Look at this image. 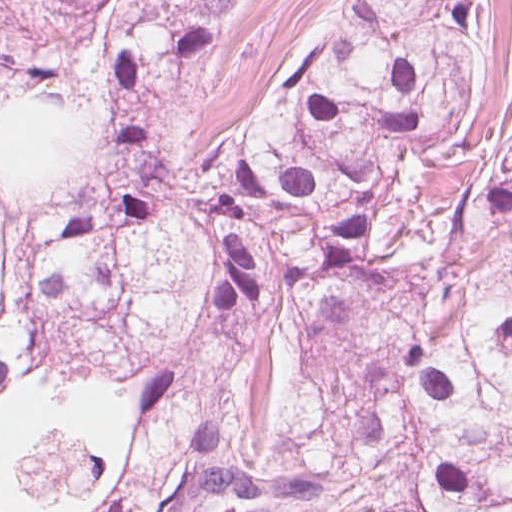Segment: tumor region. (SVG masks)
Returning <instances> with one entry per match:
<instances>
[{"mask_svg":"<svg viewBox=\"0 0 512 512\" xmlns=\"http://www.w3.org/2000/svg\"><path fill=\"white\" fill-rule=\"evenodd\" d=\"M243 0H0V512H512L493 0H340L200 170Z\"/></svg>","mask_w":512,"mask_h":512,"instance_id":"tumor-region-1","label":"tumor region"}]
</instances>
